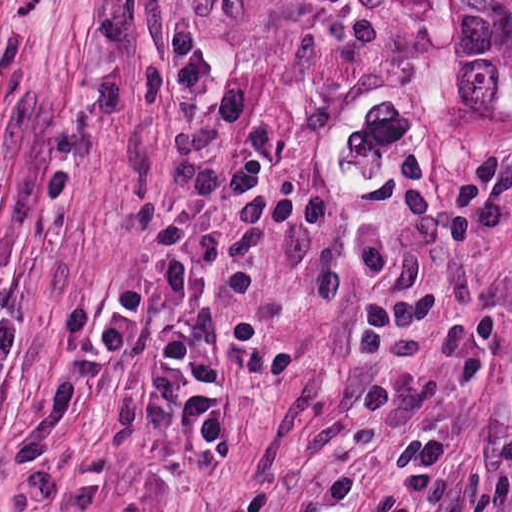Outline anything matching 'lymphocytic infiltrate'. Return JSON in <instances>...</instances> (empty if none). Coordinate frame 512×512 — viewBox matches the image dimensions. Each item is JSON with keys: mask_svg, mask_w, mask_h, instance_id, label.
I'll list each match as a JSON object with an SVG mask.
<instances>
[{"mask_svg": "<svg viewBox=\"0 0 512 512\" xmlns=\"http://www.w3.org/2000/svg\"><path fill=\"white\" fill-rule=\"evenodd\" d=\"M506 317L484 310L428 335L376 493L378 512H454L451 441L434 428L447 388L475 383L502 352Z\"/></svg>", "mask_w": 512, "mask_h": 512, "instance_id": "f902f5d3", "label": "lymphocytic infiltrate"}]
</instances>
